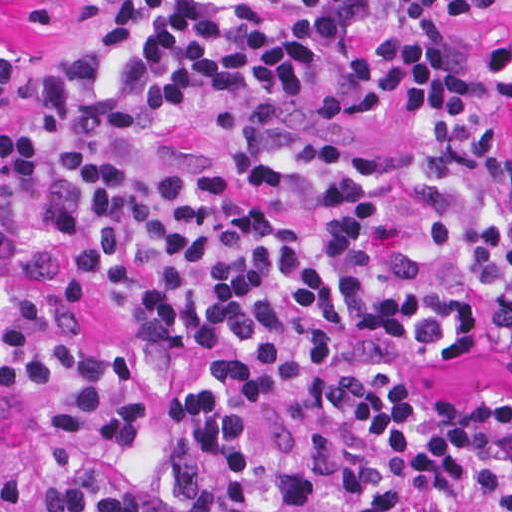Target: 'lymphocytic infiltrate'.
I'll list each match as a JSON object with an SVG mask.
<instances>
[{
    "label": "lymphocytic infiltrate",
    "instance_id": "obj_1",
    "mask_svg": "<svg viewBox=\"0 0 512 512\" xmlns=\"http://www.w3.org/2000/svg\"><path fill=\"white\" fill-rule=\"evenodd\" d=\"M112 6L0 45V512H512V390L381 348H512V0Z\"/></svg>",
    "mask_w": 512,
    "mask_h": 512
}]
</instances>
